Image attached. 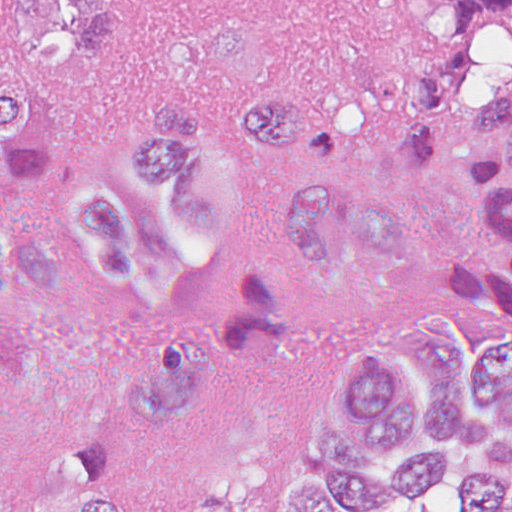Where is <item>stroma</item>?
<instances>
[{
  "label": "stroma",
  "mask_w": 512,
  "mask_h": 512,
  "mask_svg": "<svg viewBox=\"0 0 512 512\" xmlns=\"http://www.w3.org/2000/svg\"><path fill=\"white\" fill-rule=\"evenodd\" d=\"M20 1L0 0V11ZM445 45L420 15L379 12L365 0H115L108 51L48 91L53 163L11 197L17 228L53 258L54 277L11 292L10 310L30 331L33 380L0 458L1 496L29 509L48 499L68 448L118 426L151 361L217 327L224 289L172 303L134 300L98 279L61 235L60 200L83 178H117L127 127L158 105L225 123L265 92H301L310 131L263 174L255 240L273 232L302 176L331 171L395 211L406 264L363 299L306 303L284 374L259 387L228 386L197 408L190 427L132 474L133 512H283L290 489L321 483L312 429L343 425L334 380L353 353L383 350L426 407L435 384L401 339L404 324L452 325L483 366L512 341L427 278L431 258L494 250V222L474 185L470 121L416 168L387 141L399 77L419 62H442ZM376 512L467 510L456 481Z\"/></svg>",
  "instance_id": "obj_1"
}]
</instances>
